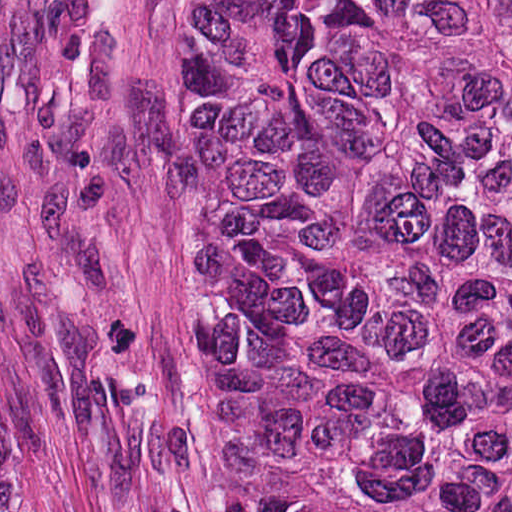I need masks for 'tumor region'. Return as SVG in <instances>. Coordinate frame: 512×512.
<instances>
[{
	"label": "tumor region",
	"instance_id": "1",
	"mask_svg": "<svg viewBox=\"0 0 512 512\" xmlns=\"http://www.w3.org/2000/svg\"><path fill=\"white\" fill-rule=\"evenodd\" d=\"M178 333L193 512H512V0H184Z\"/></svg>",
	"mask_w": 512,
	"mask_h": 512
}]
</instances>
